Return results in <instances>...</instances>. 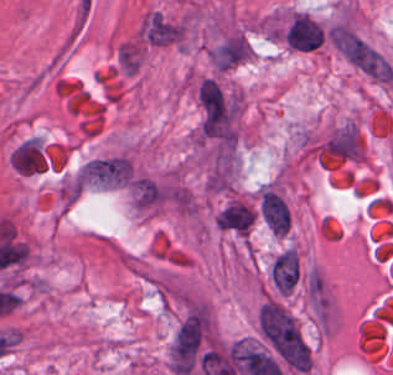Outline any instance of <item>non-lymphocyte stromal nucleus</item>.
Wrapping results in <instances>:
<instances>
[{
    "mask_svg": "<svg viewBox=\"0 0 393 375\" xmlns=\"http://www.w3.org/2000/svg\"><path fill=\"white\" fill-rule=\"evenodd\" d=\"M263 339L293 371H308L309 352L290 314L278 303L266 302L258 311Z\"/></svg>",
    "mask_w": 393,
    "mask_h": 375,
    "instance_id": "1",
    "label": "non-lymphocyte stromal nucleus"
},
{
    "mask_svg": "<svg viewBox=\"0 0 393 375\" xmlns=\"http://www.w3.org/2000/svg\"><path fill=\"white\" fill-rule=\"evenodd\" d=\"M269 276L276 289L282 293L293 290L299 278V260L292 250H284L269 268Z\"/></svg>",
    "mask_w": 393,
    "mask_h": 375,
    "instance_id": "4",
    "label": "non-lymphocyte stromal nucleus"
},
{
    "mask_svg": "<svg viewBox=\"0 0 393 375\" xmlns=\"http://www.w3.org/2000/svg\"><path fill=\"white\" fill-rule=\"evenodd\" d=\"M253 221V209L238 202H231L215 216V224L219 229L238 235H247Z\"/></svg>",
    "mask_w": 393,
    "mask_h": 375,
    "instance_id": "3",
    "label": "non-lymphocyte stromal nucleus"
},
{
    "mask_svg": "<svg viewBox=\"0 0 393 375\" xmlns=\"http://www.w3.org/2000/svg\"><path fill=\"white\" fill-rule=\"evenodd\" d=\"M258 206L268 231L276 236H283L288 229L289 216L287 206L280 195L266 187L260 193Z\"/></svg>",
    "mask_w": 393,
    "mask_h": 375,
    "instance_id": "2",
    "label": "non-lymphocyte stromal nucleus"
},
{
    "mask_svg": "<svg viewBox=\"0 0 393 375\" xmlns=\"http://www.w3.org/2000/svg\"><path fill=\"white\" fill-rule=\"evenodd\" d=\"M198 95L207 116L221 117V90L211 78L200 81Z\"/></svg>",
    "mask_w": 393,
    "mask_h": 375,
    "instance_id": "5",
    "label": "non-lymphocyte stromal nucleus"
}]
</instances>
